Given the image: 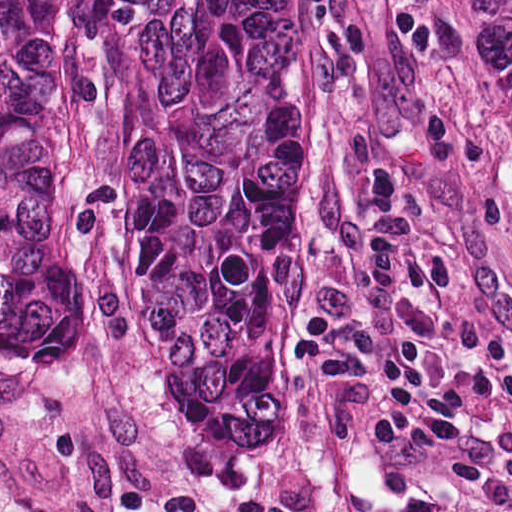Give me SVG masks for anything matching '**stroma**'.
Here are the masks:
<instances>
[{
  "mask_svg": "<svg viewBox=\"0 0 512 512\" xmlns=\"http://www.w3.org/2000/svg\"><path fill=\"white\" fill-rule=\"evenodd\" d=\"M309 1L320 175L261 422L231 452L150 409L120 377L0 355V512H512V167L451 1ZM379 160L403 173L417 255L397 327L458 389L482 487L370 457L369 364L331 392L288 377L301 318L349 311L356 288L333 238L371 218L364 181Z\"/></svg>",
  "mask_w": 512,
  "mask_h": 512,
  "instance_id": "35a3bbf8",
  "label": "stroma"
}]
</instances>
